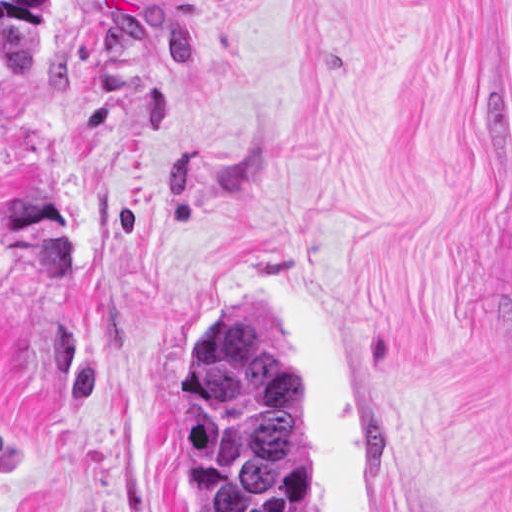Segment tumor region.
Returning a JSON list of instances; mask_svg holds the SVG:
<instances>
[{"mask_svg":"<svg viewBox=\"0 0 512 512\" xmlns=\"http://www.w3.org/2000/svg\"><path fill=\"white\" fill-rule=\"evenodd\" d=\"M50 18L51 0H0L9 74L35 62ZM177 457L196 478V512H329L280 343L241 289L211 291L181 332Z\"/></svg>","mask_w":512,"mask_h":512,"instance_id":"obj_1","label":"tumor region"}]
</instances>
